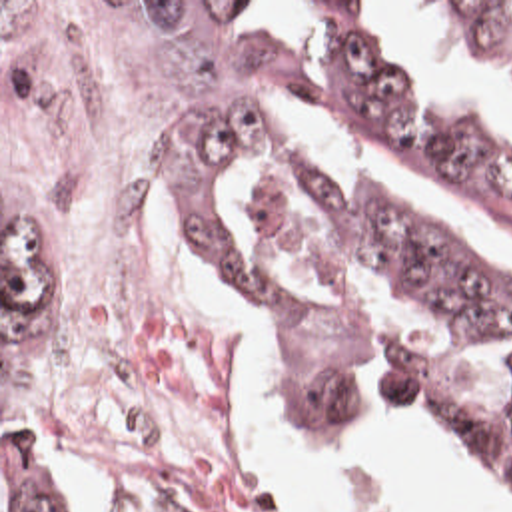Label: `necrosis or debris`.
Returning a JSON list of instances; mask_svg holds the SVG:
<instances>
[{"label":"necrosis or debris","mask_w":512,"mask_h":512,"mask_svg":"<svg viewBox=\"0 0 512 512\" xmlns=\"http://www.w3.org/2000/svg\"><path fill=\"white\" fill-rule=\"evenodd\" d=\"M194 2H2V274L30 417L220 512L278 489L178 168Z\"/></svg>","instance_id":"necrosis-or-debris-1"}]
</instances>
